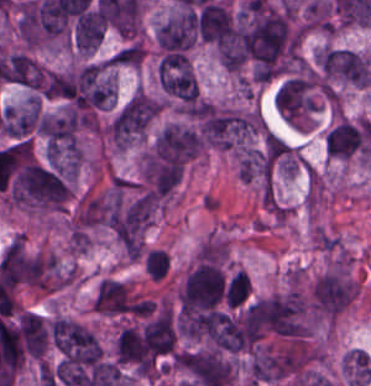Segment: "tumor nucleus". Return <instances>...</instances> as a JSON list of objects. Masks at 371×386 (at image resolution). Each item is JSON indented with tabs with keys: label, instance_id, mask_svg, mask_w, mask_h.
I'll list each match as a JSON object with an SVG mask.
<instances>
[{
	"label": "tumor nucleus",
	"instance_id": "1",
	"mask_svg": "<svg viewBox=\"0 0 371 386\" xmlns=\"http://www.w3.org/2000/svg\"><path fill=\"white\" fill-rule=\"evenodd\" d=\"M52 341L65 361L97 364L103 354L95 336L76 321L56 319L50 327Z\"/></svg>",
	"mask_w": 371,
	"mask_h": 386
},
{
	"label": "tumor nucleus",
	"instance_id": "2",
	"mask_svg": "<svg viewBox=\"0 0 371 386\" xmlns=\"http://www.w3.org/2000/svg\"><path fill=\"white\" fill-rule=\"evenodd\" d=\"M41 117L37 97L4 105L0 116L1 132L15 139H24L40 132Z\"/></svg>",
	"mask_w": 371,
	"mask_h": 386
},
{
	"label": "tumor nucleus",
	"instance_id": "3",
	"mask_svg": "<svg viewBox=\"0 0 371 386\" xmlns=\"http://www.w3.org/2000/svg\"><path fill=\"white\" fill-rule=\"evenodd\" d=\"M45 67L27 52H8L1 57V77L7 83L30 92L39 89Z\"/></svg>",
	"mask_w": 371,
	"mask_h": 386
},
{
	"label": "tumor nucleus",
	"instance_id": "4",
	"mask_svg": "<svg viewBox=\"0 0 371 386\" xmlns=\"http://www.w3.org/2000/svg\"><path fill=\"white\" fill-rule=\"evenodd\" d=\"M104 29L99 12L91 5L73 24V46L81 52H93L100 44Z\"/></svg>",
	"mask_w": 371,
	"mask_h": 386
}]
</instances>
